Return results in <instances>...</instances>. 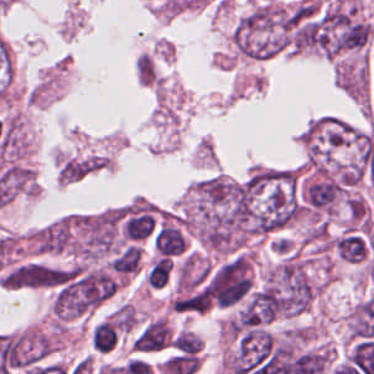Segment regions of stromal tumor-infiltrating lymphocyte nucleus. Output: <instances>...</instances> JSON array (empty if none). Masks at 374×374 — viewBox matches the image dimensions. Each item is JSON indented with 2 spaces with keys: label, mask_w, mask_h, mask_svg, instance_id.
I'll return each instance as SVG.
<instances>
[{
  "label": "stromal tumor-infiltrating lymphocyte nucleus",
  "mask_w": 374,
  "mask_h": 374,
  "mask_svg": "<svg viewBox=\"0 0 374 374\" xmlns=\"http://www.w3.org/2000/svg\"><path fill=\"white\" fill-rule=\"evenodd\" d=\"M172 274V259L164 256L157 255L149 261L144 280L149 287L160 288L167 284Z\"/></svg>",
  "instance_id": "1"
},
{
  "label": "stromal tumor-infiltrating lymphocyte nucleus",
  "mask_w": 374,
  "mask_h": 374,
  "mask_svg": "<svg viewBox=\"0 0 374 374\" xmlns=\"http://www.w3.org/2000/svg\"><path fill=\"white\" fill-rule=\"evenodd\" d=\"M154 247L158 253L173 255L183 250V239L170 225H162L154 236Z\"/></svg>",
  "instance_id": "2"
},
{
  "label": "stromal tumor-infiltrating lymphocyte nucleus",
  "mask_w": 374,
  "mask_h": 374,
  "mask_svg": "<svg viewBox=\"0 0 374 374\" xmlns=\"http://www.w3.org/2000/svg\"><path fill=\"white\" fill-rule=\"evenodd\" d=\"M153 226V219L147 211L130 216L126 221L123 232L126 238L137 241L149 236L153 230Z\"/></svg>",
  "instance_id": "3"
},
{
  "label": "stromal tumor-infiltrating lymphocyte nucleus",
  "mask_w": 374,
  "mask_h": 374,
  "mask_svg": "<svg viewBox=\"0 0 374 374\" xmlns=\"http://www.w3.org/2000/svg\"><path fill=\"white\" fill-rule=\"evenodd\" d=\"M141 260V250L136 245H128L111 263L117 273H137Z\"/></svg>",
  "instance_id": "4"
}]
</instances>
